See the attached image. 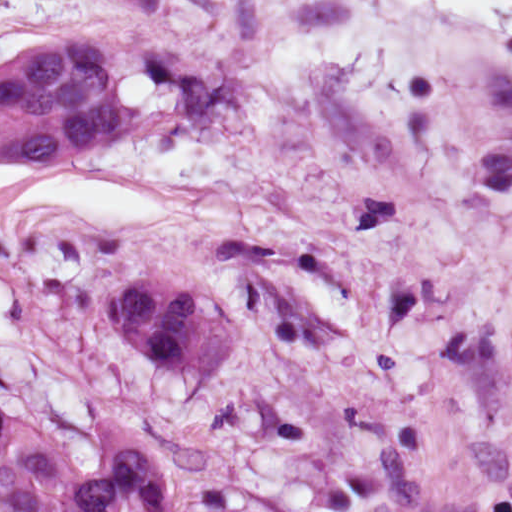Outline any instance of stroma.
<instances>
[{
  "instance_id": "35a3bbf8",
  "label": "stroma",
  "mask_w": 512,
  "mask_h": 512,
  "mask_svg": "<svg viewBox=\"0 0 512 512\" xmlns=\"http://www.w3.org/2000/svg\"><path fill=\"white\" fill-rule=\"evenodd\" d=\"M112 40L133 132L81 158L147 222L0 220L35 356L0 407L81 469L121 418L206 432L298 512H512V46L403 0H0V66ZM229 303L226 369L108 324L115 285Z\"/></svg>"
}]
</instances>
